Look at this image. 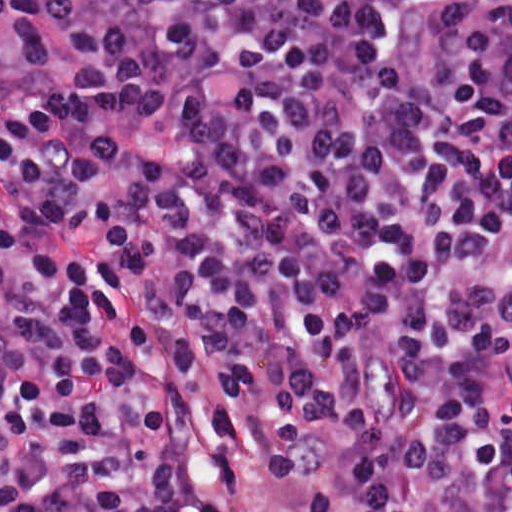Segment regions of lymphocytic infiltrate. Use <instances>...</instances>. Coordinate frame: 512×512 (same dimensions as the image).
Listing matches in <instances>:
<instances>
[{"instance_id":"lymphocytic-infiltrate-1","label":"lymphocytic infiltrate","mask_w":512,"mask_h":512,"mask_svg":"<svg viewBox=\"0 0 512 512\" xmlns=\"http://www.w3.org/2000/svg\"><path fill=\"white\" fill-rule=\"evenodd\" d=\"M512 0H13L0 512H512Z\"/></svg>"}]
</instances>
